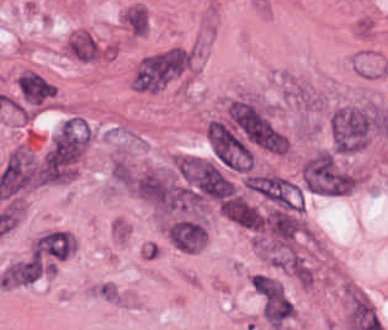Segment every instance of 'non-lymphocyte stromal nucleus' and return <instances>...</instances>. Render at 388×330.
<instances>
[{
  "instance_id": "1",
  "label": "non-lymphocyte stromal nucleus",
  "mask_w": 388,
  "mask_h": 330,
  "mask_svg": "<svg viewBox=\"0 0 388 330\" xmlns=\"http://www.w3.org/2000/svg\"><path fill=\"white\" fill-rule=\"evenodd\" d=\"M84 128L79 123L59 128L42 157L43 181H63L83 154Z\"/></svg>"
},
{
  "instance_id": "2",
  "label": "non-lymphocyte stromal nucleus",
  "mask_w": 388,
  "mask_h": 330,
  "mask_svg": "<svg viewBox=\"0 0 388 330\" xmlns=\"http://www.w3.org/2000/svg\"><path fill=\"white\" fill-rule=\"evenodd\" d=\"M302 188L307 192L338 196L340 193V173L333 154L317 152L302 163Z\"/></svg>"
},
{
  "instance_id": "3",
  "label": "non-lymphocyte stromal nucleus",
  "mask_w": 388,
  "mask_h": 330,
  "mask_svg": "<svg viewBox=\"0 0 388 330\" xmlns=\"http://www.w3.org/2000/svg\"><path fill=\"white\" fill-rule=\"evenodd\" d=\"M244 186L252 193L281 208L297 209L295 185L274 174H248Z\"/></svg>"
},
{
  "instance_id": "4",
  "label": "non-lymphocyte stromal nucleus",
  "mask_w": 388,
  "mask_h": 330,
  "mask_svg": "<svg viewBox=\"0 0 388 330\" xmlns=\"http://www.w3.org/2000/svg\"><path fill=\"white\" fill-rule=\"evenodd\" d=\"M261 220L274 244H285L302 230L299 208L269 205Z\"/></svg>"
},
{
  "instance_id": "5",
  "label": "non-lymphocyte stromal nucleus",
  "mask_w": 388,
  "mask_h": 330,
  "mask_svg": "<svg viewBox=\"0 0 388 330\" xmlns=\"http://www.w3.org/2000/svg\"><path fill=\"white\" fill-rule=\"evenodd\" d=\"M71 238L60 229L43 231L32 245V251L41 259L59 260L70 253Z\"/></svg>"
},
{
  "instance_id": "6",
  "label": "non-lymphocyte stromal nucleus",
  "mask_w": 388,
  "mask_h": 330,
  "mask_svg": "<svg viewBox=\"0 0 388 330\" xmlns=\"http://www.w3.org/2000/svg\"><path fill=\"white\" fill-rule=\"evenodd\" d=\"M41 275V259L29 255L10 263L2 272L0 281L6 285H18L32 281Z\"/></svg>"
},
{
  "instance_id": "7",
  "label": "non-lymphocyte stromal nucleus",
  "mask_w": 388,
  "mask_h": 330,
  "mask_svg": "<svg viewBox=\"0 0 388 330\" xmlns=\"http://www.w3.org/2000/svg\"><path fill=\"white\" fill-rule=\"evenodd\" d=\"M123 21L130 33L140 35L147 26V17L139 6H132L123 14Z\"/></svg>"
}]
</instances>
